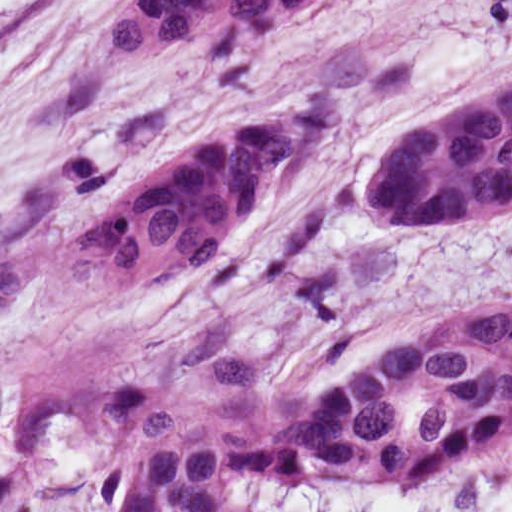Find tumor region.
Wrapping results in <instances>:
<instances>
[{"label": "tumor region", "mask_w": 512, "mask_h": 512, "mask_svg": "<svg viewBox=\"0 0 512 512\" xmlns=\"http://www.w3.org/2000/svg\"><path fill=\"white\" fill-rule=\"evenodd\" d=\"M344 0H124L100 38L133 62H214L309 32Z\"/></svg>", "instance_id": "e687c5a6"}]
</instances>
